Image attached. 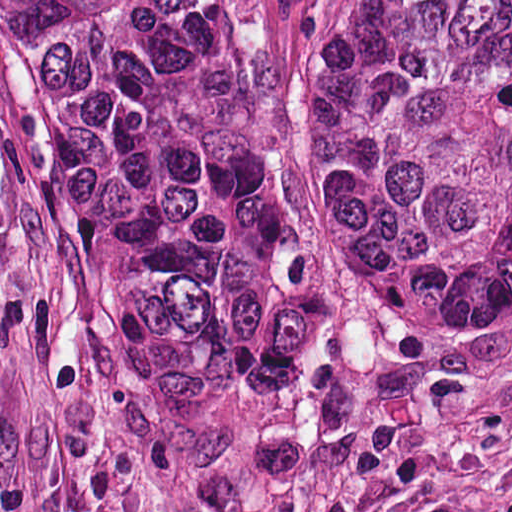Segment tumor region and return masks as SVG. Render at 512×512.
Wrapping results in <instances>:
<instances>
[{"mask_svg": "<svg viewBox=\"0 0 512 512\" xmlns=\"http://www.w3.org/2000/svg\"><path fill=\"white\" fill-rule=\"evenodd\" d=\"M109 401L241 451L304 401L326 250L512 310V0H0Z\"/></svg>", "mask_w": 512, "mask_h": 512, "instance_id": "e687c5a6", "label": "tumor region"}]
</instances>
